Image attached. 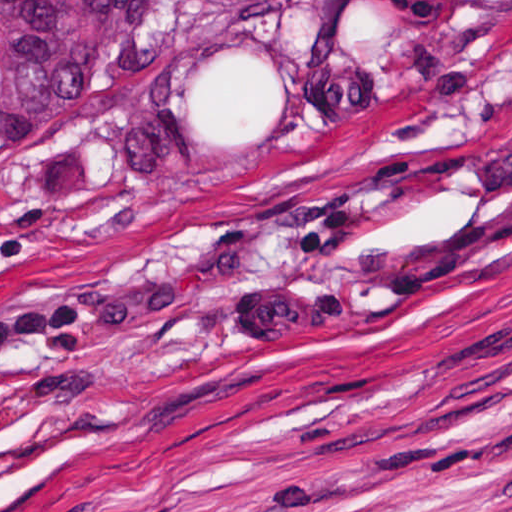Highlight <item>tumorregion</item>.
Returning a JSON list of instances; mask_svg holds the SVG:
<instances>
[{
	"mask_svg": "<svg viewBox=\"0 0 512 512\" xmlns=\"http://www.w3.org/2000/svg\"><path fill=\"white\" fill-rule=\"evenodd\" d=\"M512 0H0V187L56 134L162 123L182 163L277 155L319 111L419 85Z\"/></svg>",
	"mask_w": 512,
	"mask_h": 512,
	"instance_id": "obj_1",
	"label": "tumor region"
}]
</instances>
